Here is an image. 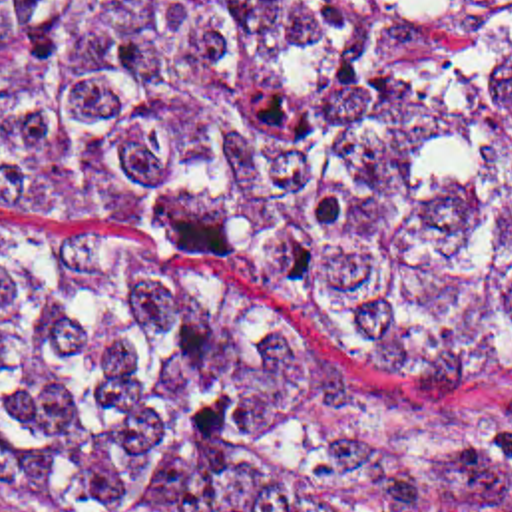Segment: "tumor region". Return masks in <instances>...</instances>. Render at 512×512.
Returning a JSON list of instances; mask_svg holds the SVG:
<instances>
[{
	"instance_id": "1",
	"label": "tumor region",
	"mask_w": 512,
	"mask_h": 512,
	"mask_svg": "<svg viewBox=\"0 0 512 512\" xmlns=\"http://www.w3.org/2000/svg\"><path fill=\"white\" fill-rule=\"evenodd\" d=\"M0 196L512 373V0H0ZM0 505L512 512V419L0 242Z\"/></svg>"
}]
</instances>
